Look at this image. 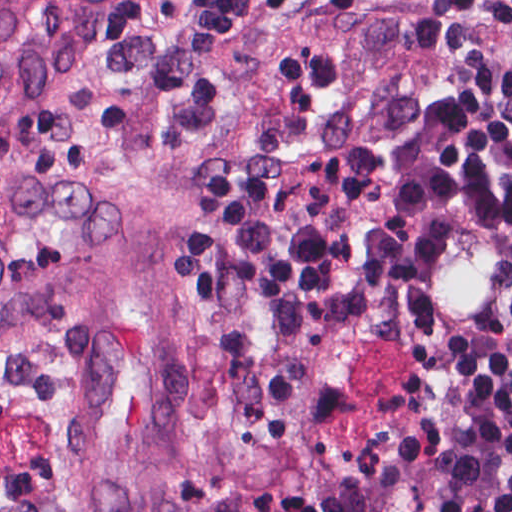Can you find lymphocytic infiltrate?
I'll list each match as a JSON object with an SVG mask.
<instances>
[{
    "label": "lymphocytic infiltrate",
    "mask_w": 512,
    "mask_h": 512,
    "mask_svg": "<svg viewBox=\"0 0 512 512\" xmlns=\"http://www.w3.org/2000/svg\"><path fill=\"white\" fill-rule=\"evenodd\" d=\"M174 107L239 411L299 404L325 335L393 314L438 215L512 241V0H177ZM397 512H512V321L455 377Z\"/></svg>",
    "instance_id": "f902f5d3"
}]
</instances>
